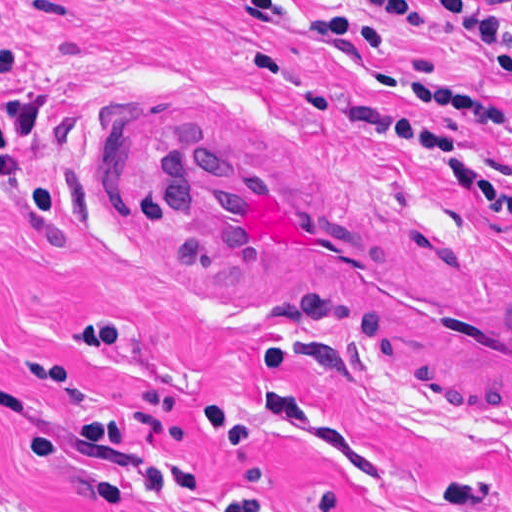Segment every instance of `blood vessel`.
Wrapping results in <instances>:
<instances>
[{
	"instance_id": "obj_1",
	"label": "blood vessel",
	"mask_w": 512,
	"mask_h": 512,
	"mask_svg": "<svg viewBox=\"0 0 512 512\" xmlns=\"http://www.w3.org/2000/svg\"><path fill=\"white\" fill-rule=\"evenodd\" d=\"M224 106L110 142L167 278L229 310L295 313L386 387L512 424V257Z\"/></svg>"
}]
</instances>
